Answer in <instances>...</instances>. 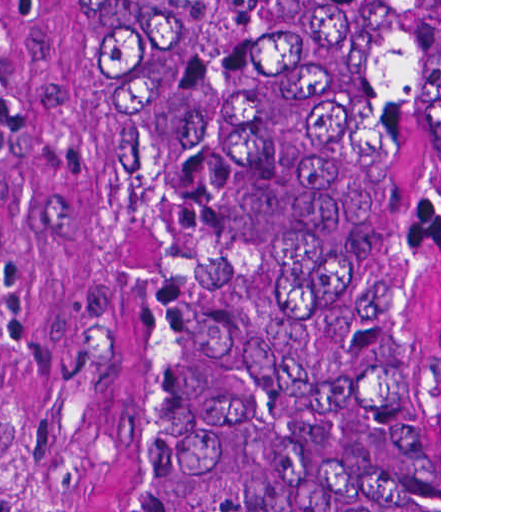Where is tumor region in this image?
I'll return each mask as SVG.
<instances>
[{
	"instance_id": "e687c5a6",
	"label": "tumor region",
	"mask_w": 512,
	"mask_h": 512,
	"mask_svg": "<svg viewBox=\"0 0 512 512\" xmlns=\"http://www.w3.org/2000/svg\"><path fill=\"white\" fill-rule=\"evenodd\" d=\"M111 341L49 512H439L434 1H72Z\"/></svg>"
}]
</instances>
